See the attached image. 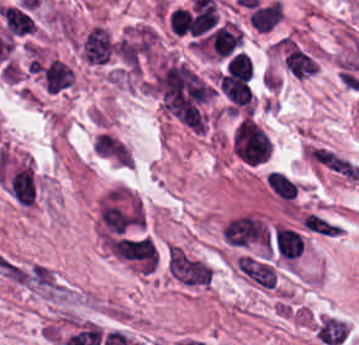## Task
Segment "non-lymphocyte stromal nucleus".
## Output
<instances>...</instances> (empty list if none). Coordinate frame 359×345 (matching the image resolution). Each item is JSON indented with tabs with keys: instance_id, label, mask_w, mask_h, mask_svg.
Here are the masks:
<instances>
[{
	"instance_id": "a72fc3eb",
	"label": "non-lymphocyte stromal nucleus",
	"mask_w": 359,
	"mask_h": 345,
	"mask_svg": "<svg viewBox=\"0 0 359 345\" xmlns=\"http://www.w3.org/2000/svg\"><path fill=\"white\" fill-rule=\"evenodd\" d=\"M239 266L247 280L255 286L271 288L276 284V272L270 262L256 255L241 254Z\"/></svg>"
},
{
	"instance_id": "dd21d789",
	"label": "non-lymphocyte stromal nucleus",
	"mask_w": 359,
	"mask_h": 345,
	"mask_svg": "<svg viewBox=\"0 0 359 345\" xmlns=\"http://www.w3.org/2000/svg\"><path fill=\"white\" fill-rule=\"evenodd\" d=\"M170 276L188 285H207L211 279L210 265L177 245H170L167 257Z\"/></svg>"
},
{
	"instance_id": "fc2b8d12",
	"label": "non-lymphocyte stromal nucleus",
	"mask_w": 359,
	"mask_h": 345,
	"mask_svg": "<svg viewBox=\"0 0 359 345\" xmlns=\"http://www.w3.org/2000/svg\"><path fill=\"white\" fill-rule=\"evenodd\" d=\"M267 183L276 196L289 200L296 191L295 182L279 171L267 174Z\"/></svg>"
},
{
	"instance_id": "81446118",
	"label": "non-lymphocyte stromal nucleus",
	"mask_w": 359,
	"mask_h": 345,
	"mask_svg": "<svg viewBox=\"0 0 359 345\" xmlns=\"http://www.w3.org/2000/svg\"><path fill=\"white\" fill-rule=\"evenodd\" d=\"M305 228L327 235H334L338 232V224L313 213H306L304 220Z\"/></svg>"
},
{
	"instance_id": "3746e769",
	"label": "non-lymphocyte stromal nucleus",
	"mask_w": 359,
	"mask_h": 345,
	"mask_svg": "<svg viewBox=\"0 0 359 345\" xmlns=\"http://www.w3.org/2000/svg\"><path fill=\"white\" fill-rule=\"evenodd\" d=\"M313 156L328 169L346 177L349 180H358L359 170L351 162L337 153L329 149L316 147Z\"/></svg>"
}]
</instances>
